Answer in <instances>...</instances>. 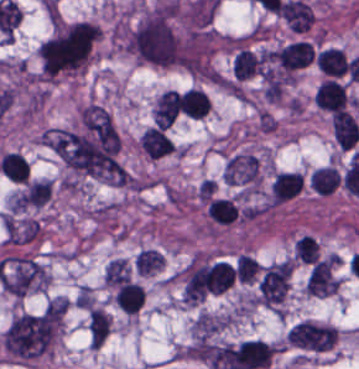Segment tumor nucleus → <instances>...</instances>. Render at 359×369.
Masks as SVG:
<instances>
[{
	"label": "tumor nucleus",
	"instance_id": "tumor-nucleus-1",
	"mask_svg": "<svg viewBox=\"0 0 359 369\" xmlns=\"http://www.w3.org/2000/svg\"><path fill=\"white\" fill-rule=\"evenodd\" d=\"M132 55L160 67L183 65L176 1L160 0L125 35Z\"/></svg>",
	"mask_w": 359,
	"mask_h": 369
},
{
	"label": "tumor nucleus",
	"instance_id": "tumor-nucleus-2",
	"mask_svg": "<svg viewBox=\"0 0 359 369\" xmlns=\"http://www.w3.org/2000/svg\"><path fill=\"white\" fill-rule=\"evenodd\" d=\"M100 37L98 27L82 20H56L39 49L45 78L74 74L89 61Z\"/></svg>",
	"mask_w": 359,
	"mask_h": 369
}]
</instances>
